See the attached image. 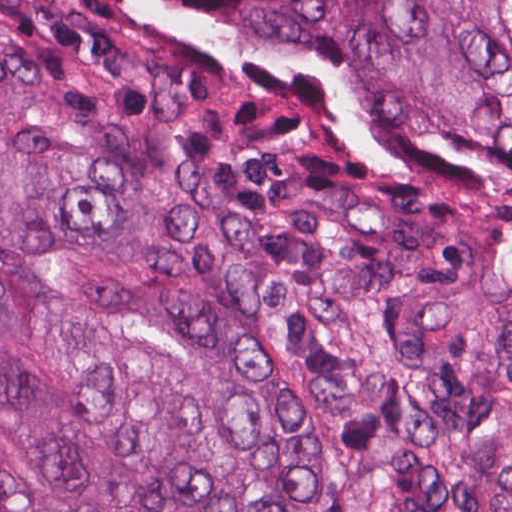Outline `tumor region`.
Returning <instances> with one entry per match:
<instances>
[{
    "label": "tumor region",
    "instance_id": "tumor-region-1",
    "mask_svg": "<svg viewBox=\"0 0 512 512\" xmlns=\"http://www.w3.org/2000/svg\"><path fill=\"white\" fill-rule=\"evenodd\" d=\"M0 512H512V0H0Z\"/></svg>",
    "mask_w": 512,
    "mask_h": 512
}]
</instances>
